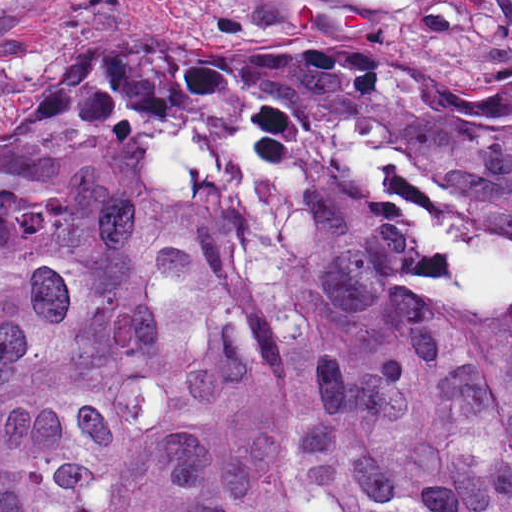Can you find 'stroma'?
Listing matches in <instances>:
<instances>
[{
  "label": "stroma",
  "instance_id": "obj_1",
  "mask_svg": "<svg viewBox=\"0 0 512 512\" xmlns=\"http://www.w3.org/2000/svg\"><path fill=\"white\" fill-rule=\"evenodd\" d=\"M352 51L408 74H512V0H0V145L65 132L66 67Z\"/></svg>",
  "mask_w": 512,
  "mask_h": 512
}]
</instances>
